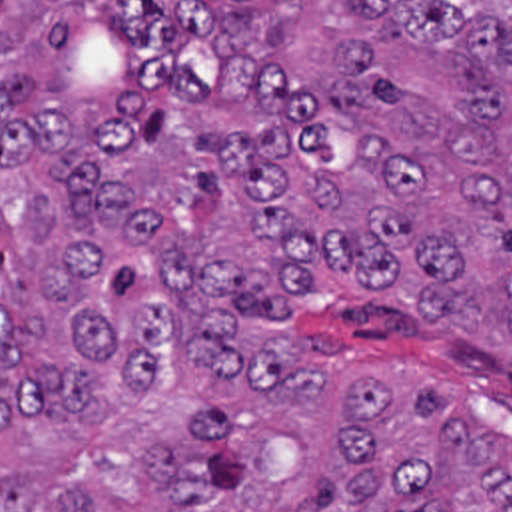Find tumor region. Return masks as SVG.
Listing matches in <instances>:
<instances>
[{
	"label": "tumor region",
	"instance_id": "obj_1",
	"mask_svg": "<svg viewBox=\"0 0 512 512\" xmlns=\"http://www.w3.org/2000/svg\"><path fill=\"white\" fill-rule=\"evenodd\" d=\"M303 298L512 370V0H0V512H512Z\"/></svg>",
	"mask_w": 512,
	"mask_h": 512
}]
</instances>
